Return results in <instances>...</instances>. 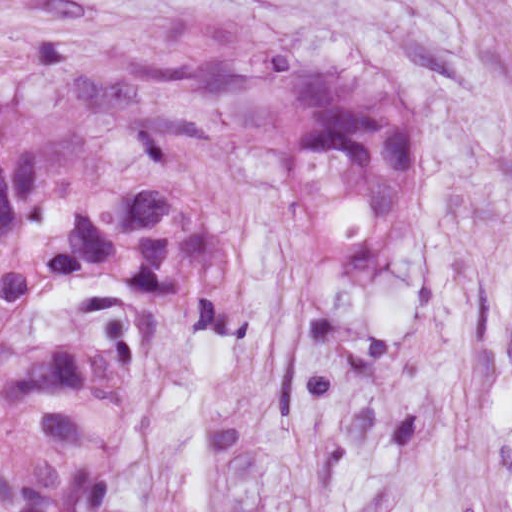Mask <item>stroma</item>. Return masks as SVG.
Instances as JSON below:
<instances>
[{"label":"stroma","mask_w":512,"mask_h":512,"mask_svg":"<svg viewBox=\"0 0 512 512\" xmlns=\"http://www.w3.org/2000/svg\"><path fill=\"white\" fill-rule=\"evenodd\" d=\"M177 7L415 71L394 288L343 278L282 145L256 171V322H169L107 512H512V0H0V70L84 67Z\"/></svg>","instance_id":"35a3bbf8"}]
</instances>
